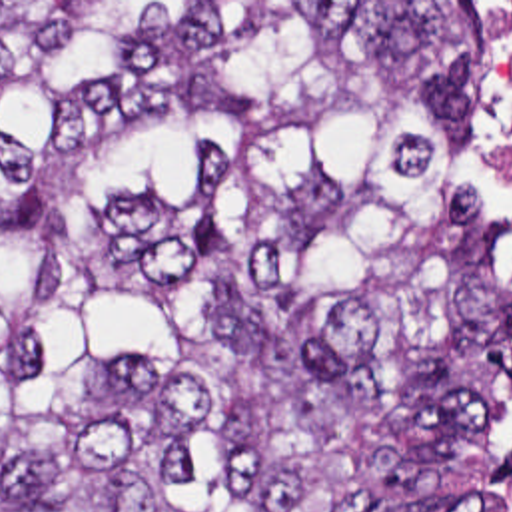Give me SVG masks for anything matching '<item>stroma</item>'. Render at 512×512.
Returning a JSON list of instances; mask_svg holds the SVG:
<instances>
[{"mask_svg":"<svg viewBox=\"0 0 512 512\" xmlns=\"http://www.w3.org/2000/svg\"><path fill=\"white\" fill-rule=\"evenodd\" d=\"M0 2H471L479 14V112L471 138L469 180L477 188L489 222L493 226V250L497 258V281L512 293V232L497 218L487 162H485V28L479 2H512V0H0ZM503 397V393H501ZM501 407V399H499ZM497 407V431H501Z\"/></svg>","mask_w":512,"mask_h":512,"instance_id":"obj_1","label":"stroma"}]
</instances>
